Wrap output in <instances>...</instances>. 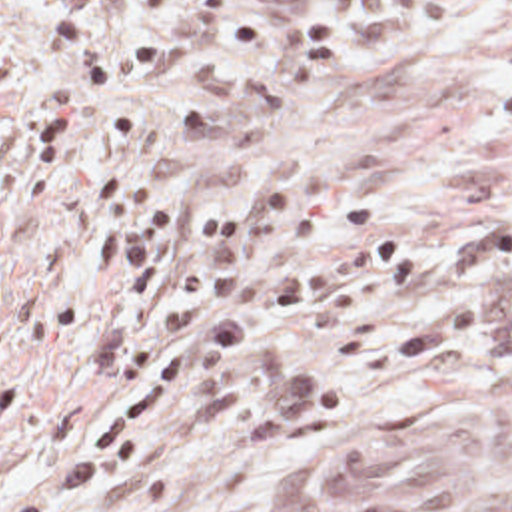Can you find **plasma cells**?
<instances>
[{
	"instance_id": "1",
	"label": "plasma cells",
	"mask_w": 512,
	"mask_h": 512,
	"mask_svg": "<svg viewBox=\"0 0 512 512\" xmlns=\"http://www.w3.org/2000/svg\"><path fill=\"white\" fill-rule=\"evenodd\" d=\"M464 355L476 367V390L490 404H512V213L464 239L430 313L369 345L365 369H434Z\"/></svg>"
}]
</instances>
